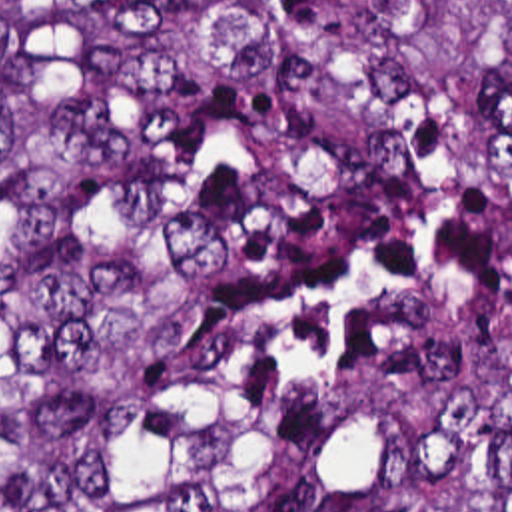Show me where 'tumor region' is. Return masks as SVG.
I'll return each instance as SVG.
<instances>
[{
	"label": "tumor region",
	"mask_w": 512,
	"mask_h": 512,
	"mask_svg": "<svg viewBox=\"0 0 512 512\" xmlns=\"http://www.w3.org/2000/svg\"><path fill=\"white\" fill-rule=\"evenodd\" d=\"M0 512H512V0H0Z\"/></svg>",
	"instance_id": "1"
}]
</instances>
